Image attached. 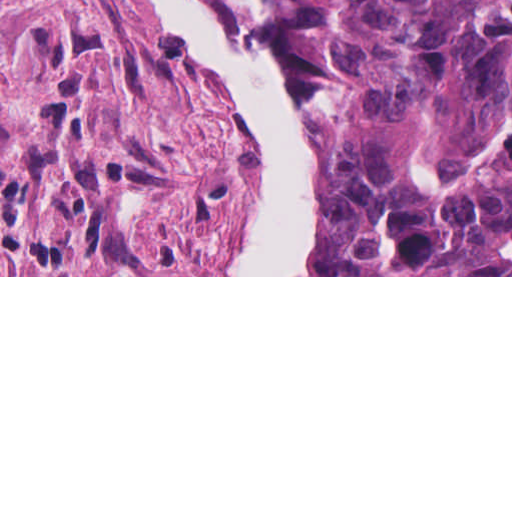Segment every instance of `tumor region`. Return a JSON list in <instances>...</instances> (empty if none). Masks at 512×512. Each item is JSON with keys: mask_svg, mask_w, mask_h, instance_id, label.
I'll list each match as a JSON object with an SVG mask.
<instances>
[{"mask_svg": "<svg viewBox=\"0 0 512 512\" xmlns=\"http://www.w3.org/2000/svg\"><path fill=\"white\" fill-rule=\"evenodd\" d=\"M315 99L309 275H512V0H263Z\"/></svg>", "mask_w": 512, "mask_h": 512, "instance_id": "e687c5a6", "label": "tumor region"}]
</instances>
